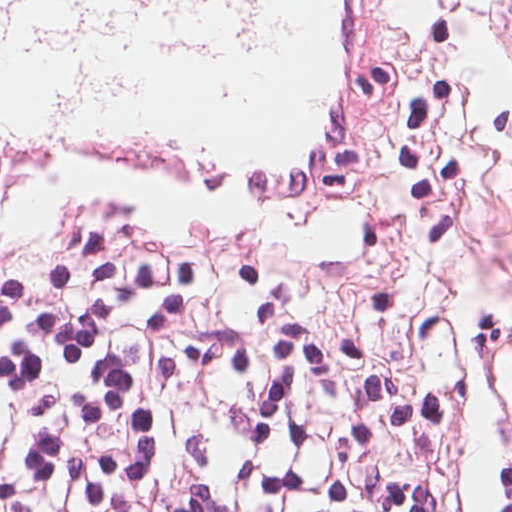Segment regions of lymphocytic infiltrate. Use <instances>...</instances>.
<instances>
[{
  "mask_svg": "<svg viewBox=\"0 0 512 512\" xmlns=\"http://www.w3.org/2000/svg\"><path fill=\"white\" fill-rule=\"evenodd\" d=\"M467 308L469 377L404 395L211 259L41 242L0 281V512H512V303Z\"/></svg>",
  "mask_w": 512,
  "mask_h": 512,
  "instance_id": "f902f5d3",
  "label": "lymphocytic infiltrate"
}]
</instances>
